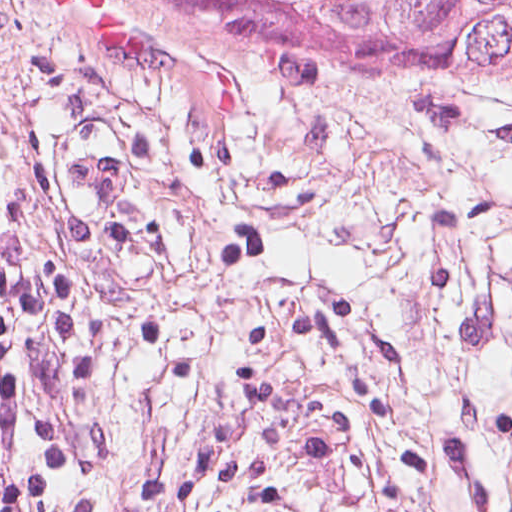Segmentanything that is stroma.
Here are the masks:
<instances>
[{
  "mask_svg": "<svg viewBox=\"0 0 512 512\" xmlns=\"http://www.w3.org/2000/svg\"><path fill=\"white\" fill-rule=\"evenodd\" d=\"M105 112L138 181L75 228L43 138ZM0 306L71 512H512V88L0 0Z\"/></svg>",
  "mask_w": 512,
  "mask_h": 512,
  "instance_id": "stroma-1",
  "label": "stroma"
}]
</instances>
